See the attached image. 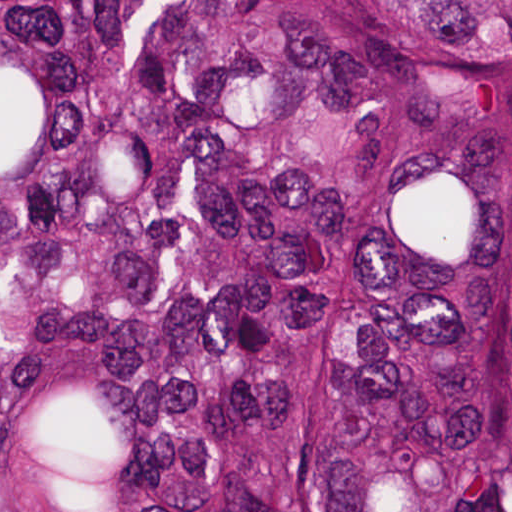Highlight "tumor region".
<instances>
[{
  "instance_id": "e687c5a6",
  "label": "tumor region",
  "mask_w": 512,
  "mask_h": 512,
  "mask_svg": "<svg viewBox=\"0 0 512 512\" xmlns=\"http://www.w3.org/2000/svg\"><path fill=\"white\" fill-rule=\"evenodd\" d=\"M0 512H512V0H0Z\"/></svg>"
}]
</instances>
